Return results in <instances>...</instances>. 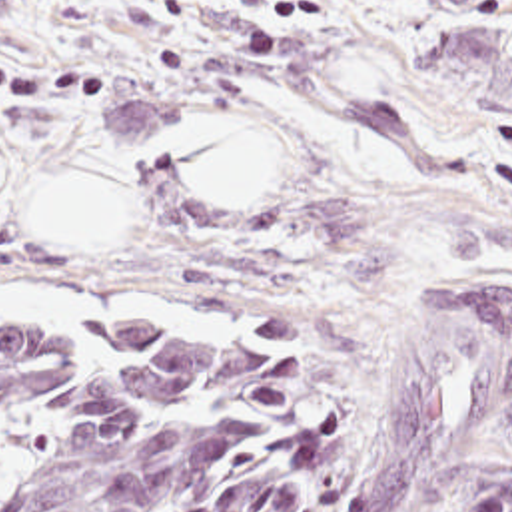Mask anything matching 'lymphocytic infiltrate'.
<instances>
[{"label": "lymphocytic infiltrate", "instance_id": "obj_1", "mask_svg": "<svg viewBox=\"0 0 512 512\" xmlns=\"http://www.w3.org/2000/svg\"><path fill=\"white\" fill-rule=\"evenodd\" d=\"M83 67L49 69L0 55V107L39 103L53 109H103L109 99V73Z\"/></svg>", "mask_w": 512, "mask_h": 512}]
</instances>
